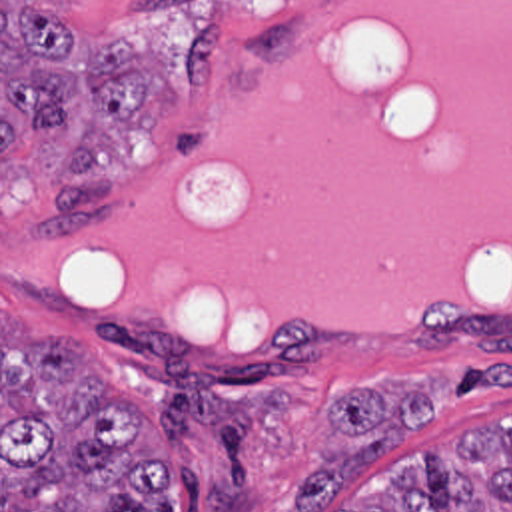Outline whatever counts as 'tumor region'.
Returning a JSON list of instances; mask_svg holds the SVG:
<instances>
[{"label":"tumor region","mask_w":512,"mask_h":512,"mask_svg":"<svg viewBox=\"0 0 512 512\" xmlns=\"http://www.w3.org/2000/svg\"><path fill=\"white\" fill-rule=\"evenodd\" d=\"M62 8L2 6V158L60 128L70 136L42 224L80 236L114 222L102 168L160 118V72L124 40L92 32L70 48ZM357 451L321 461L292 489V512L331 495L429 417V399L359 387L331 405ZM357 512H512V435L475 437L407 473ZM2 512H180V453L122 403L64 340L28 342L2 312Z\"/></svg>","instance_id":"tumor-region-1"}]
</instances>
